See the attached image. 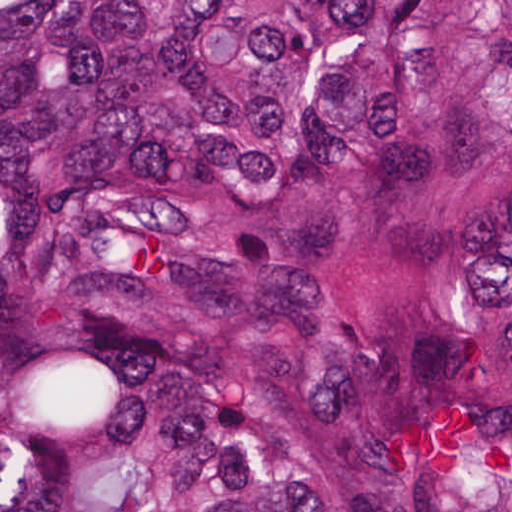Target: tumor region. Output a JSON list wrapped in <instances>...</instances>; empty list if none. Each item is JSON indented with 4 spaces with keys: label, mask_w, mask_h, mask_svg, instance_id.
Segmentation results:
<instances>
[{
    "label": "tumor region",
    "mask_w": 512,
    "mask_h": 512,
    "mask_svg": "<svg viewBox=\"0 0 512 512\" xmlns=\"http://www.w3.org/2000/svg\"><path fill=\"white\" fill-rule=\"evenodd\" d=\"M0 512H512V0H0Z\"/></svg>",
    "instance_id": "tumor-region-1"
}]
</instances>
